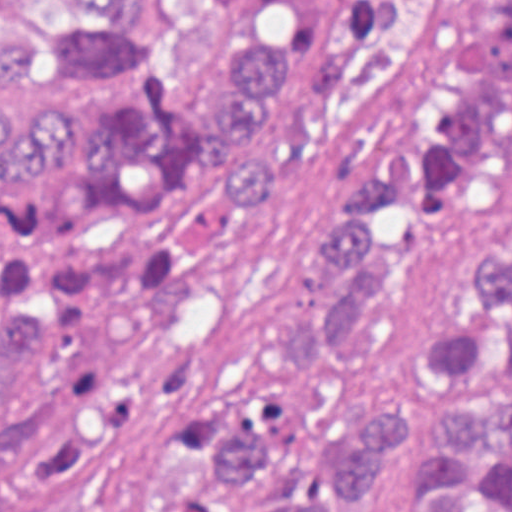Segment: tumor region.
I'll list each match as a JSON object with an SVG mask.
<instances>
[{
    "instance_id": "1",
    "label": "tumor region",
    "mask_w": 512,
    "mask_h": 512,
    "mask_svg": "<svg viewBox=\"0 0 512 512\" xmlns=\"http://www.w3.org/2000/svg\"><path fill=\"white\" fill-rule=\"evenodd\" d=\"M73 20L0 28V70L102 117L0 94V512H110L135 426L172 397L236 212L263 208L332 138L324 98L406 0H54ZM512 170V0H476L471 43L307 262L327 299L248 338L258 372L335 348L404 285L461 196ZM226 196H222L221 186ZM407 379L448 405L407 512H512V233ZM295 420L245 399L209 435L224 487L259 475ZM409 413L318 465L295 509L373 496Z\"/></svg>"
}]
</instances>
